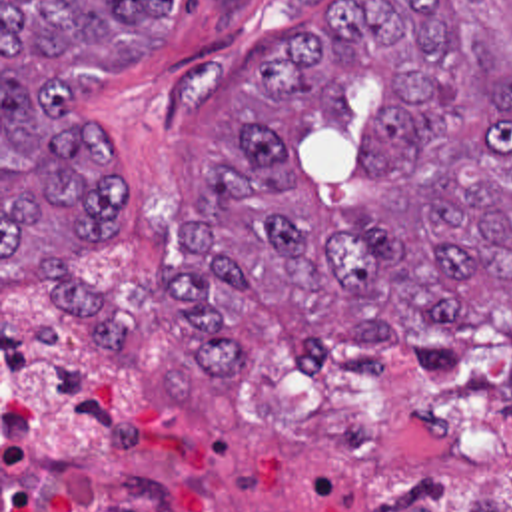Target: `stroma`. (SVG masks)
<instances>
[{"instance_id":"stroma-1","label":"stroma","mask_w":512,"mask_h":512,"mask_svg":"<svg viewBox=\"0 0 512 512\" xmlns=\"http://www.w3.org/2000/svg\"><path fill=\"white\" fill-rule=\"evenodd\" d=\"M345 1L180 0L168 45L152 57L104 75H84V115L120 139L122 213L104 237H84L80 257L94 279L132 305L130 343H102L48 303L40 289L2 297V0H0V512H359L409 488H359L339 478L301 444L128 446L100 472L76 480H2V311L50 319L62 331L100 347L166 393L168 367L194 347L174 323L168 275L186 263L184 217L204 183L208 159L234 163L242 117L274 121L288 147L295 181L309 191L325 235L357 229L349 205L377 191L367 133L385 105L379 85L355 79L349 97L357 117L315 101L262 103L246 77L278 65L293 41L317 29ZM262 319L290 329L270 307L240 295L226 323L242 333L250 359L240 373H208L182 403L230 395L252 369ZM487 319L511 317L489 309ZM483 323V321H481ZM465 325L461 351L481 327ZM383 367L425 371L403 349L373 351ZM443 498H423L435 512H512V476L497 466H467L437 478Z\"/></svg>"}]
</instances>
